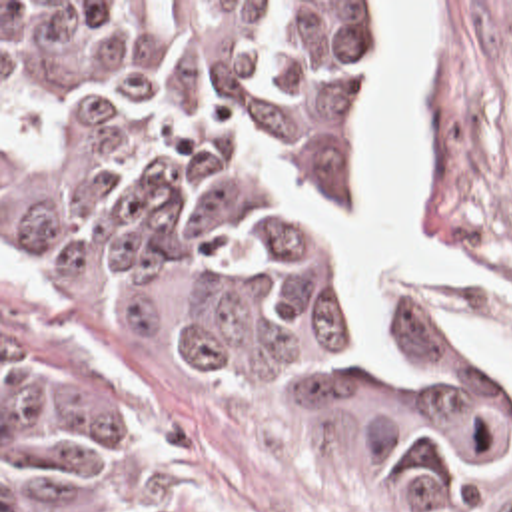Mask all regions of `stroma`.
Wrapping results in <instances>:
<instances>
[{
    "instance_id": "1",
    "label": "stroma",
    "mask_w": 512,
    "mask_h": 512,
    "mask_svg": "<svg viewBox=\"0 0 512 512\" xmlns=\"http://www.w3.org/2000/svg\"><path fill=\"white\" fill-rule=\"evenodd\" d=\"M2 2H441L447 46L419 104L425 236L467 246L511 283L469 276L391 278L387 313L351 295L333 218L345 214L357 126L373 78L339 126L325 208V270L339 301L377 335L447 343L512 381L455 337L449 319L512 347V0H0V512H2ZM84 363L102 381V415L124 457L120 512H453L429 473L335 417H302L182 361L74 293L66 311Z\"/></svg>"
}]
</instances>
